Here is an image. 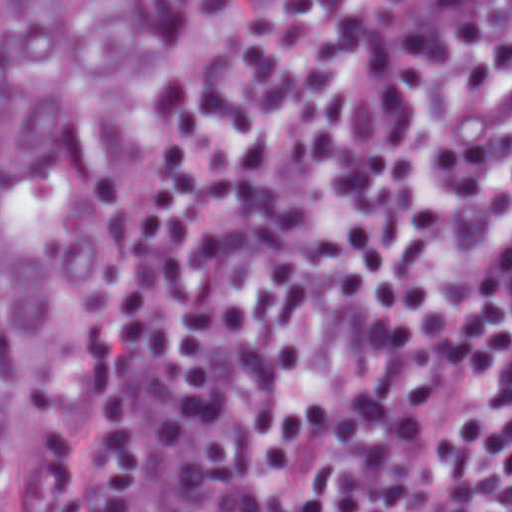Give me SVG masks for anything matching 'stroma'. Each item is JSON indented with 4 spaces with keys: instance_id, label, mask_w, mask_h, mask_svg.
Returning a JSON list of instances; mask_svg holds the SVG:
<instances>
[{
    "instance_id": "obj_1",
    "label": "stroma",
    "mask_w": 512,
    "mask_h": 512,
    "mask_svg": "<svg viewBox=\"0 0 512 512\" xmlns=\"http://www.w3.org/2000/svg\"><path fill=\"white\" fill-rule=\"evenodd\" d=\"M1 1H512V0H0V512H1Z\"/></svg>"
}]
</instances>
